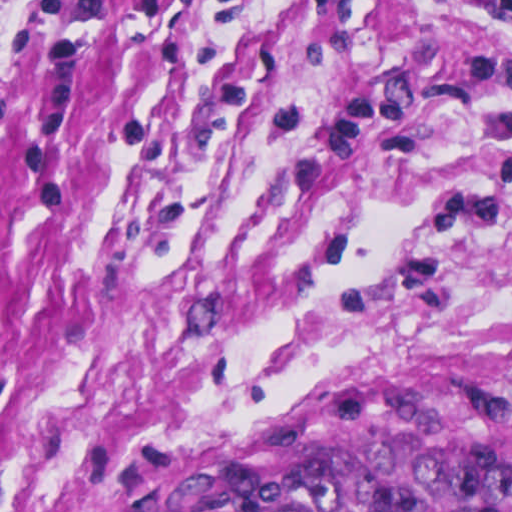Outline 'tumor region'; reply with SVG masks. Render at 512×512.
I'll return each instance as SVG.
<instances>
[{
    "instance_id": "obj_1",
    "label": "tumor region",
    "mask_w": 512,
    "mask_h": 512,
    "mask_svg": "<svg viewBox=\"0 0 512 512\" xmlns=\"http://www.w3.org/2000/svg\"><path fill=\"white\" fill-rule=\"evenodd\" d=\"M147 512H512V386L272 412Z\"/></svg>"
}]
</instances>
